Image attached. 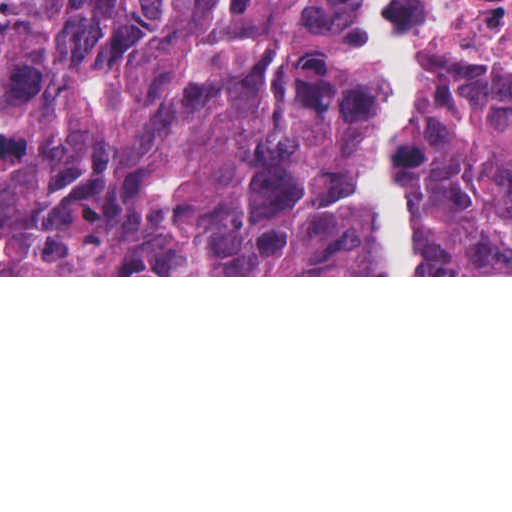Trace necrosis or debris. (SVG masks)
Returning <instances> with one entry per match:
<instances>
[{
  "mask_svg": "<svg viewBox=\"0 0 512 512\" xmlns=\"http://www.w3.org/2000/svg\"><path fill=\"white\" fill-rule=\"evenodd\" d=\"M462 20L479 38L512 37V0H456Z\"/></svg>",
  "mask_w": 512,
  "mask_h": 512,
  "instance_id": "1",
  "label": "necrosis or debris"
}]
</instances>
